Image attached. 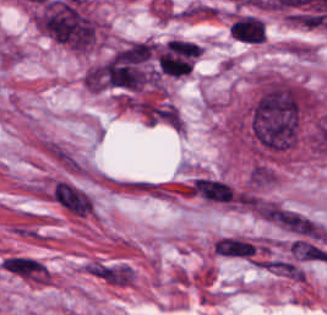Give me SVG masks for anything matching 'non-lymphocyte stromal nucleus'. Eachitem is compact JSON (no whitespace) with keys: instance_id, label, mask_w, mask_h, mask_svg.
<instances>
[{"instance_id":"obj_1","label":"non-lymphocyte stromal nucleus","mask_w":327,"mask_h":315,"mask_svg":"<svg viewBox=\"0 0 327 315\" xmlns=\"http://www.w3.org/2000/svg\"><path fill=\"white\" fill-rule=\"evenodd\" d=\"M37 149L65 171L82 172L85 165L73 148L58 138L38 137Z\"/></svg>"},{"instance_id":"obj_2","label":"non-lymphocyte stromal nucleus","mask_w":327,"mask_h":315,"mask_svg":"<svg viewBox=\"0 0 327 315\" xmlns=\"http://www.w3.org/2000/svg\"><path fill=\"white\" fill-rule=\"evenodd\" d=\"M52 198L55 203L70 213L84 218L92 214V201L90 197L64 181L56 182Z\"/></svg>"},{"instance_id":"obj_3","label":"non-lymphocyte stromal nucleus","mask_w":327,"mask_h":315,"mask_svg":"<svg viewBox=\"0 0 327 315\" xmlns=\"http://www.w3.org/2000/svg\"><path fill=\"white\" fill-rule=\"evenodd\" d=\"M0 266L8 272L36 283H48V271L36 258L27 255H8Z\"/></svg>"}]
</instances>
